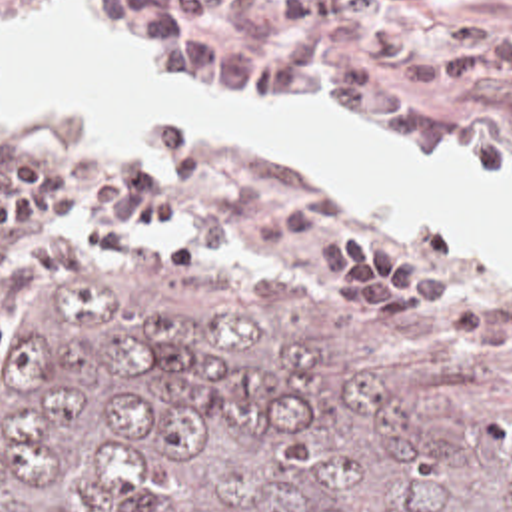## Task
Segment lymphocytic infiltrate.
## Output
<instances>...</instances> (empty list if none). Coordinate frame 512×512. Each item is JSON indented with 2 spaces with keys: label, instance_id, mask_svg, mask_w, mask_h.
I'll return each mask as SVG.
<instances>
[{
  "label": "lymphocytic infiltrate",
  "instance_id": "1",
  "mask_svg": "<svg viewBox=\"0 0 512 512\" xmlns=\"http://www.w3.org/2000/svg\"><path fill=\"white\" fill-rule=\"evenodd\" d=\"M215 154L183 123L151 127V148L101 164L73 198L66 170L28 156L0 178V286L46 272H70L75 238L111 254L139 246L145 234L181 220L201 254L247 262L299 242L325 224V194L295 176L255 204L229 212H191L213 182ZM341 286L373 324H405L409 314L443 298V278L407 256L379 226L335 230Z\"/></svg>",
  "mask_w": 512,
  "mask_h": 512
}]
</instances>
